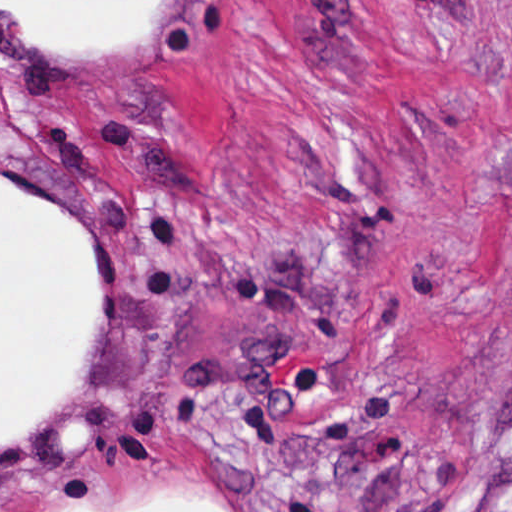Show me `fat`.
Masks as SVG:
<instances>
[{
  "label": "fat",
  "instance_id": "1",
  "mask_svg": "<svg viewBox=\"0 0 512 512\" xmlns=\"http://www.w3.org/2000/svg\"><path fill=\"white\" fill-rule=\"evenodd\" d=\"M147 0H1L49 40H96L135 23ZM92 319V284L75 225L51 202L1 180V450L60 391ZM177 505V506H174ZM144 512H227L175 503Z\"/></svg>",
  "mask_w": 512,
  "mask_h": 512
}]
</instances>
